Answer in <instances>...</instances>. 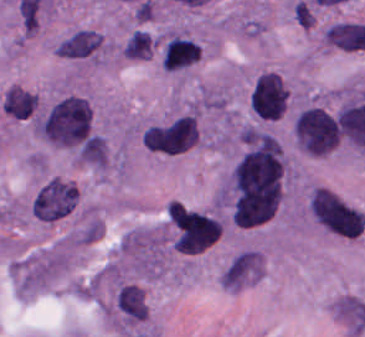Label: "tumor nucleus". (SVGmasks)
<instances>
[{
	"label": "tumor nucleus",
	"instance_id": "obj_2",
	"mask_svg": "<svg viewBox=\"0 0 365 337\" xmlns=\"http://www.w3.org/2000/svg\"><path fill=\"white\" fill-rule=\"evenodd\" d=\"M308 212L319 227L339 237L353 238L365 224L361 212L333 191L318 185L309 194Z\"/></svg>",
	"mask_w": 365,
	"mask_h": 337
},
{
	"label": "tumor nucleus",
	"instance_id": "obj_6",
	"mask_svg": "<svg viewBox=\"0 0 365 337\" xmlns=\"http://www.w3.org/2000/svg\"><path fill=\"white\" fill-rule=\"evenodd\" d=\"M200 55V45L184 31L170 29L160 38L159 63L168 71H180Z\"/></svg>",
	"mask_w": 365,
	"mask_h": 337
},
{
	"label": "tumor nucleus",
	"instance_id": "obj_10",
	"mask_svg": "<svg viewBox=\"0 0 365 337\" xmlns=\"http://www.w3.org/2000/svg\"><path fill=\"white\" fill-rule=\"evenodd\" d=\"M123 58L146 59L154 52V43L149 32L133 27L125 36L120 48Z\"/></svg>",
	"mask_w": 365,
	"mask_h": 337
},
{
	"label": "tumor nucleus",
	"instance_id": "obj_9",
	"mask_svg": "<svg viewBox=\"0 0 365 337\" xmlns=\"http://www.w3.org/2000/svg\"><path fill=\"white\" fill-rule=\"evenodd\" d=\"M37 105V97L23 86L10 85L1 93V110L15 119H29Z\"/></svg>",
	"mask_w": 365,
	"mask_h": 337
},
{
	"label": "tumor nucleus",
	"instance_id": "obj_1",
	"mask_svg": "<svg viewBox=\"0 0 365 337\" xmlns=\"http://www.w3.org/2000/svg\"><path fill=\"white\" fill-rule=\"evenodd\" d=\"M33 132L51 145L78 148L92 134V107L83 96L69 93L40 110Z\"/></svg>",
	"mask_w": 365,
	"mask_h": 337
},
{
	"label": "tumor nucleus",
	"instance_id": "obj_3",
	"mask_svg": "<svg viewBox=\"0 0 365 337\" xmlns=\"http://www.w3.org/2000/svg\"><path fill=\"white\" fill-rule=\"evenodd\" d=\"M167 218L174 250L196 253L210 246L218 237L221 226L200 211L169 204Z\"/></svg>",
	"mask_w": 365,
	"mask_h": 337
},
{
	"label": "tumor nucleus",
	"instance_id": "obj_4",
	"mask_svg": "<svg viewBox=\"0 0 365 337\" xmlns=\"http://www.w3.org/2000/svg\"><path fill=\"white\" fill-rule=\"evenodd\" d=\"M78 194L66 179L50 177L41 182L31 201L30 212L40 221L62 219L77 204Z\"/></svg>",
	"mask_w": 365,
	"mask_h": 337
},
{
	"label": "tumor nucleus",
	"instance_id": "obj_7",
	"mask_svg": "<svg viewBox=\"0 0 365 337\" xmlns=\"http://www.w3.org/2000/svg\"><path fill=\"white\" fill-rule=\"evenodd\" d=\"M107 47L97 31L90 27H77L59 39L53 50L62 58L97 59Z\"/></svg>",
	"mask_w": 365,
	"mask_h": 337
},
{
	"label": "tumor nucleus",
	"instance_id": "obj_5",
	"mask_svg": "<svg viewBox=\"0 0 365 337\" xmlns=\"http://www.w3.org/2000/svg\"><path fill=\"white\" fill-rule=\"evenodd\" d=\"M106 314L111 323L125 328L144 320L146 302L141 287L130 282H117L109 299Z\"/></svg>",
	"mask_w": 365,
	"mask_h": 337
},
{
	"label": "tumor nucleus",
	"instance_id": "obj_8",
	"mask_svg": "<svg viewBox=\"0 0 365 337\" xmlns=\"http://www.w3.org/2000/svg\"><path fill=\"white\" fill-rule=\"evenodd\" d=\"M258 277H261V254L245 249L230 258L217 279L224 286H242Z\"/></svg>",
	"mask_w": 365,
	"mask_h": 337
}]
</instances>
